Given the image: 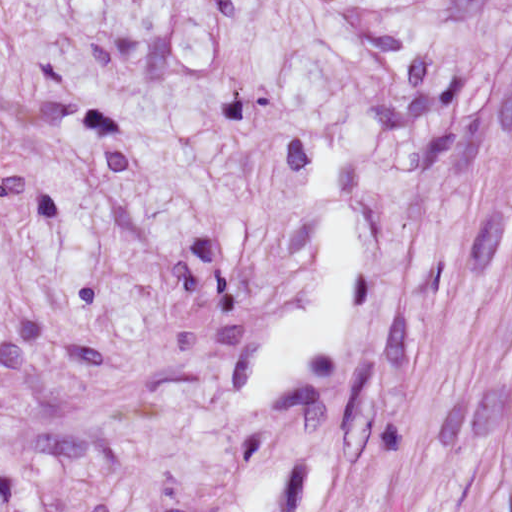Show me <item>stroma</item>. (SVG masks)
Wrapping results in <instances>:
<instances>
[{"label": "stroma", "mask_w": 512, "mask_h": 512, "mask_svg": "<svg viewBox=\"0 0 512 512\" xmlns=\"http://www.w3.org/2000/svg\"><path fill=\"white\" fill-rule=\"evenodd\" d=\"M0 512H512V0H0Z\"/></svg>", "instance_id": "obj_1"}]
</instances>
